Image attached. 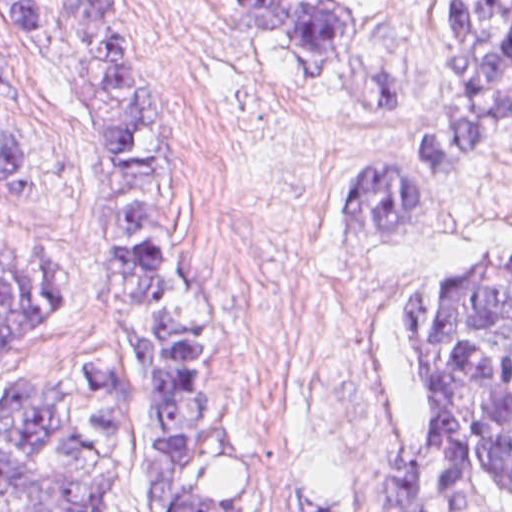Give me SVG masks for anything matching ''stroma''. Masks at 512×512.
I'll use <instances>...</instances> for the list:
<instances>
[{
  "label": "stroma",
  "instance_id": "stroma-1",
  "mask_svg": "<svg viewBox=\"0 0 512 512\" xmlns=\"http://www.w3.org/2000/svg\"><path fill=\"white\" fill-rule=\"evenodd\" d=\"M120 1L200 155L187 238L210 317L209 376L232 409L233 494L362 512L389 452L416 434L408 290L512 241V117L422 199L409 236L343 239L340 185L455 94V0H328L355 17L362 50L354 70L317 74L239 33L225 0ZM0 119L24 161L23 185L0 169V248L60 262L57 311L0 349L1 396L18 374L128 353L105 147L54 0H31V40L0 18ZM117 512H140L132 454Z\"/></svg>",
  "mask_w": 512,
  "mask_h": 512
}]
</instances>
